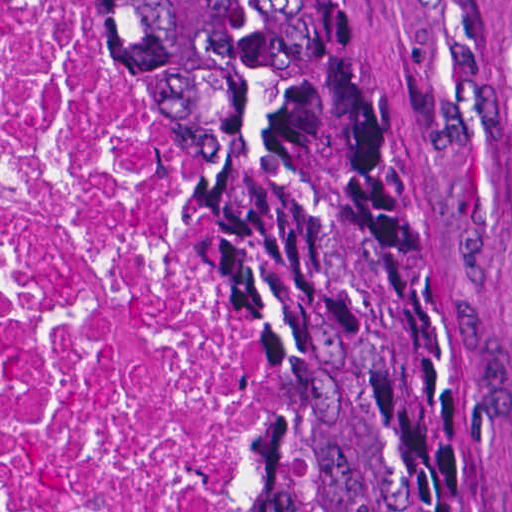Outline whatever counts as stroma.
I'll list each match as a JSON object with an SVG mask.
<instances>
[{
    "mask_svg": "<svg viewBox=\"0 0 512 512\" xmlns=\"http://www.w3.org/2000/svg\"><path fill=\"white\" fill-rule=\"evenodd\" d=\"M117 22L110 0H90ZM400 79L431 228L454 295L481 512H512V0H363ZM118 23V22H117ZM200 184L207 258L230 288L236 512L260 399V287L222 173L130 42Z\"/></svg>",
    "mask_w": 512,
    "mask_h": 512,
    "instance_id": "1",
    "label": "stroma"
}]
</instances>
